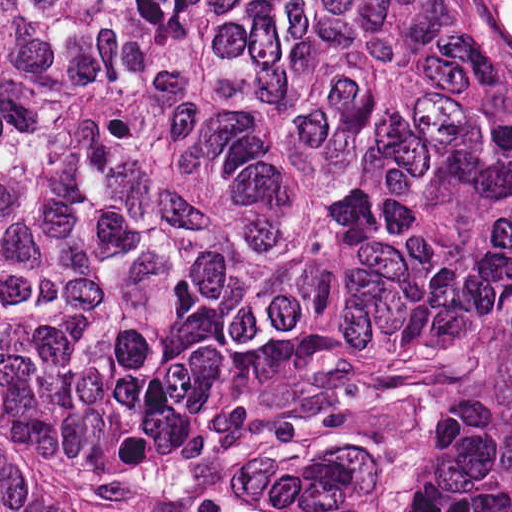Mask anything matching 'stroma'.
Returning <instances> with one entry per match:
<instances>
[{
	"mask_svg": "<svg viewBox=\"0 0 512 512\" xmlns=\"http://www.w3.org/2000/svg\"><path fill=\"white\" fill-rule=\"evenodd\" d=\"M512 88V65L509 64ZM463 361L410 414L339 435H290L254 452L249 486L337 464L365 493V512H415ZM44 512H129L95 456L8 438Z\"/></svg>",
	"mask_w": 512,
	"mask_h": 512,
	"instance_id": "stroma-1",
	"label": "stroma"
}]
</instances>
